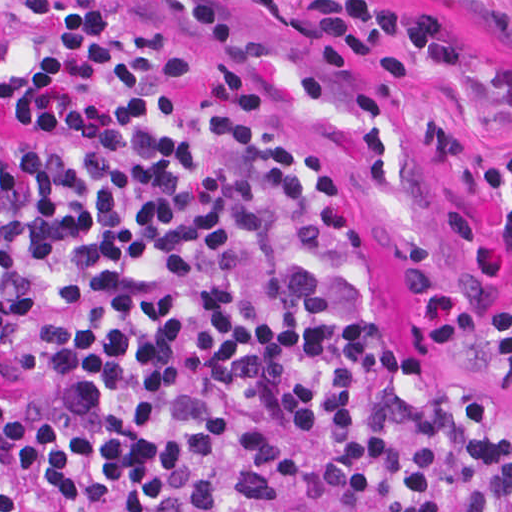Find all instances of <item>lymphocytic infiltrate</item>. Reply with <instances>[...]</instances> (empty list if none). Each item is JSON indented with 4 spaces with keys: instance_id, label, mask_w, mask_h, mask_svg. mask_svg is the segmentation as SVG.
<instances>
[{
    "instance_id": "1",
    "label": "lymphocytic infiltrate",
    "mask_w": 512,
    "mask_h": 512,
    "mask_svg": "<svg viewBox=\"0 0 512 512\" xmlns=\"http://www.w3.org/2000/svg\"><path fill=\"white\" fill-rule=\"evenodd\" d=\"M283 32L340 82L467 54L405 1L299 0ZM438 142L507 279L392 320V223L243 0H0V512H512V416L403 346L512 370V107L461 102Z\"/></svg>"
}]
</instances>
